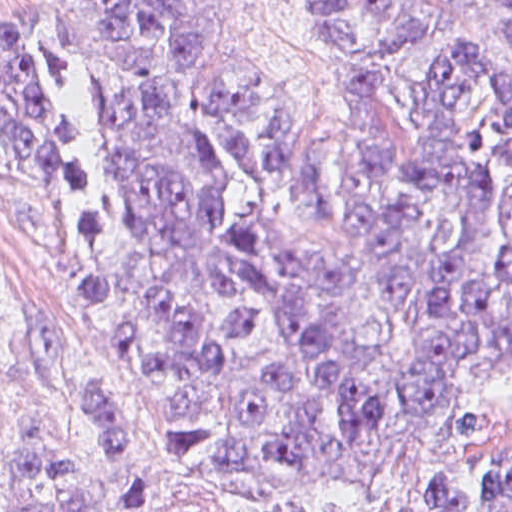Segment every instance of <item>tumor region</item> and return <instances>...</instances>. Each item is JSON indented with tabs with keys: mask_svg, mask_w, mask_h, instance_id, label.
<instances>
[{
	"mask_svg": "<svg viewBox=\"0 0 512 512\" xmlns=\"http://www.w3.org/2000/svg\"><path fill=\"white\" fill-rule=\"evenodd\" d=\"M339 135L279 113L242 0H55L88 83L79 268L135 415L204 473L336 459L512 364V0H302ZM0 124L46 131L0 55ZM125 395L62 383L10 512H126ZM299 512H512V445H456Z\"/></svg>",
	"mask_w": 512,
	"mask_h": 512,
	"instance_id": "1",
	"label": "tumor region"
}]
</instances>
